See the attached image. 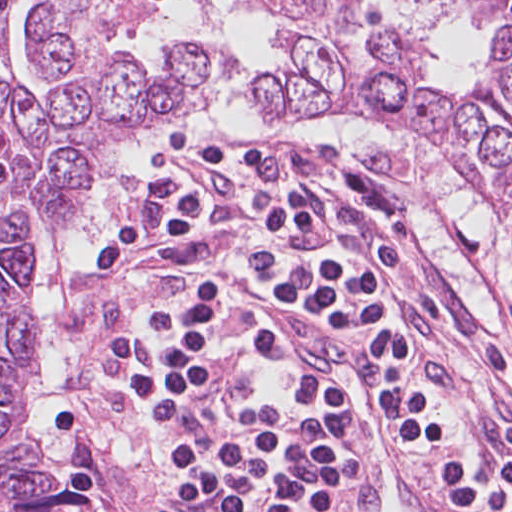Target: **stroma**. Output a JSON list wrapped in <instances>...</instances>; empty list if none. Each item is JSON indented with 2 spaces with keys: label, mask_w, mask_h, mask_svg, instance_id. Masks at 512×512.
Segmentation results:
<instances>
[{
  "label": "stroma",
  "mask_w": 512,
  "mask_h": 512,
  "mask_svg": "<svg viewBox=\"0 0 512 512\" xmlns=\"http://www.w3.org/2000/svg\"><path fill=\"white\" fill-rule=\"evenodd\" d=\"M158 1L155 0L152 8ZM184 1L192 11L190 1ZM364 1L429 45L430 83H442L461 93L482 71L487 61L489 0H481L478 11H462L450 4L428 0ZM26 2L32 3L34 8L31 23L42 3L39 0ZM23 3L0 12V17ZM117 44L125 53L121 42ZM43 77L52 81V90L40 101L47 100L63 82L70 80L94 98L83 78ZM393 125L415 134L438 153L446 166L461 175L412 123ZM107 128L109 149L125 138L111 133L108 124ZM194 136L186 138L185 142ZM179 146L166 148L156 155L152 172ZM376 155L416 189L411 170L396 154ZM466 186L474 189L467 181ZM429 212L498 299L506 289L499 273V243L459 227L443 207ZM45 238L43 227H36L33 252ZM415 271L433 293L445 317L429 313L418 316L411 324L417 337L429 349L434 361L460 383L468 413L481 438L512 460V377L494 359L470 346L482 338L486 329L459 308L441 274L419 246L415 253ZM32 308L35 312L33 299ZM98 314L94 291L84 271L79 297L65 318L70 357L65 367L63 390L52 412L53 420L64 450L85 471L99 498L73 465L74 486L95 494L97 512L102 510V504L111 507L113 512H155L154 494L161 472V453L147 426L115 387L104 365ZM42 354L41 345V357ZM30 381L31 378L26 388ZM16 439L24 440L23 434Z\"/></svg>",
  "instance_id": "obj_1"
}]
</instances>
